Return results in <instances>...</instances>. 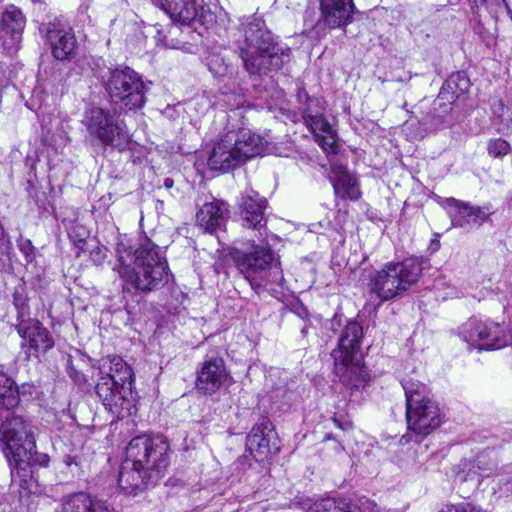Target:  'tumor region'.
<instances>
[{"label":"tumor region","instance_id":"1","mask_svg":"<svg viewBox=\"0 0 512 512\" xmlns=\"http://www.w3.org/2000/svg\"><path fill=\"white\" fill-rule=\"evenodd\" d=\"M0 512H512V0H0Z\"/></svg>","mask_w":512,"mask_h":512}]
</instances>
